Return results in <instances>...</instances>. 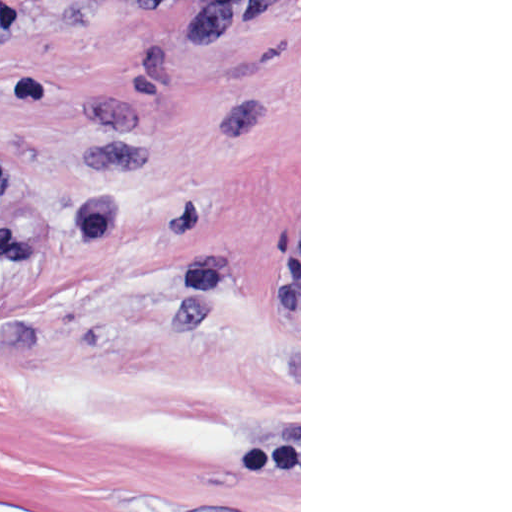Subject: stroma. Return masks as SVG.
Returning <instances> with one entry per match:
<instances>
[{
    "label": "stroma",
    "instance_id": "stroma-1",
    "mask_svg": "<svg viewBox=\"0 0 512 512\" xmlns=\"http://www.w3.org/2000/svg\"><path fill=\"white\" fill-rule=\"evenodd\" d=\"M0 157L124 201L0 277V512H301V0H0Z\"/></svg>",
    "mask_w": 512,
    "mask_h": 512
}]
</instances>
